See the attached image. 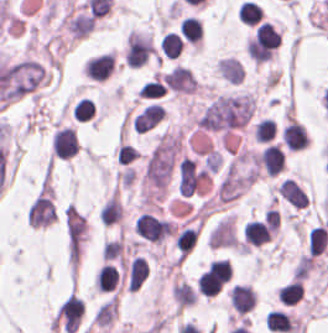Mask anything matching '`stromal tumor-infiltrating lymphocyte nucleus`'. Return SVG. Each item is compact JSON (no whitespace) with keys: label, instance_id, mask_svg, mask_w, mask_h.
<instances>
[{"label":"stromal tumor-infiltrating lymphocyte nucleus","instance_id":"bc302bb0","mask_svg":"<svg viewBox=\"0 0 328 333\" xmlns=\"http://www.w3.org/2000/svg\"><path fill=\"white\" fill-rule=\"evenodd\" d=\"M51 149L54 157L70 159L79 150L75 132L72 128L61 127L55 131L51 138Z\"/></svg>","mask_w":328,"mask_h":333},{"label":"stromal tumor-infiltrating lymphocyte nucleus","instance_id":"52c7bb5b","mask_svg":"<svg viewBox=\"0 0 328 333\" xmlns=\"http://www.w3.org/2000/svg\"><path fill=\"white\" fill-rule=\"evenodd\" d=\"M286 154L281 146L268 143L256 157V163L267 175H276L284 169Z\"/></svg>","mask_w":328,"mask_h":333},{"label":"stromal tumor-infiltrating lymphocyte nucleus","instance_id":"3290ff9b","mask_svg":"<svg viewBox=\"0 0 328 333\" xmlns=\"http://www.w3.org/2000/svg\"><path fill=\"white\" fill-rule=\"evenodd\" d=\"M281 139L286 148L299 150L305 148L309 142L306 128L294 118H287L282 130Z\"/></svg>","mask_w":328,"mask_h":333},{"label":"stromal tumor-infiltrating lymphocyte nucleus","instance_id":"abfb95fc","mask_svg":"<svg viewBox=\"0 0 328 333\" xmlns=\"http://www.w3.org/2000/svg\"><path fill=\"white\" fill-rule=\"evenodd\" d=\"M114 58L112 53L92 56L85 65V76L94 81H103L113 72Z\"/></svg>","mask_w":328,"mask_h":333},{"label":"stromal tumor-infiltrating lymphocyte nucleus","instance_id":"9ea309e8","mask_svg":"<svg viewBox=\"0 0 328 333\" xmlns=\"http://www.w3.org/2000/svg\"><path fill=\"white\" fill-rule=\"evenodd\" d=\"M229 300L237 313H246L251 310L257 301L256 292L247 285H234L230 288Z\"/></svg>","mask_w":328,"mask_h":333},{"label":"stromal tumor-infiltrating lymphocyte nucleus","instance_id":"f3e2335f","mask_svg":"<svg viewBox=\"0 0 328 333\" xmlns=\"http://www.w3.org/2000/svg\"><path fill=\"white\" fill-rule=\"evenodd\" d=\"M276 190L281 198L292 203L293 205L301 209L308 206V196L296 180L288 178L282 180L276 187Z\"/></svg>","mask_w":328,"mask_h":333},{"label":"stromal tumor-infiltrating lymphocyte nucleus","instance_id":"4f13568d","mask_svg":"<svg viewBox=\"0 0 328 333\" xmlns=\"http://www.w3.org/2000/svg\"><path fill=\"white\" fill-rule=\"evenodd\" d=\"M244 242L252 246H261L271 236V230L266 223L250 220L242 229Z\"/></svg>","mask_w":328,"mask_h":333},{"label":"stromal tumor-infiltrating lymphocyte nucleus","instance_id":"2a367800","mask_svg":"<svg viewBox=\"0 0 328 333\" xmlns=\"http://www.w3.org/2000/svg\"><path fill=\"white\" fill-rule=\"evenodd\" d=\"M265 320L271 331L287 333L297 332V319L289 313L278 309H271Z\"/></svg>","mask_w":328,"mask_h":333},{"label":"stromal tumor-infiltrating lymphocyte nucleus","instance_id":"4803ca6d","mask_svg":"<svg viewBox=\"0 0 328 333\" xmlns=\"http://www.w3.org/2000/svg\"><path fill=\"white\" fill-rule=\"evenodd\" d=\"M119 272L110 263H102L95 278V288L102 292H110L117 284Z\"/></svg>","mask_w":328,"mask_h":333},{"label":"stromal tumor-infiltrating lymphocyte nucleus","instance_id":"4245b91a","mask_svg":"<svg viewBox=\"0 0 328 333\" xmlns=\"http://www.w3.org/2000/svg\"><path fill=\"white\" fill-rule=\"evenodd\" d=\"M158 45L164 56L176 58L183 50L184 43L178 32L168 30L159 39Z\"/></svg>","mask_w":328,"mask_h":333},{"label":"stromal tumor-infiltrating lymphocyte nucleus","instance_id":"4c9ddf68","mask_svg":"<svg viewBox=\"0 0 328 333\" xmlns=\"http://www.w3.org/2000/svg\"><path fill=\"white\" fill-rule=\"evenodd\" d=\"M277 298L281 303L288 306L296 305L303 298L302 281L296 278L282 286Z\"/></svg>","mask_w":328,"mask_h":333},{"label":"stromal tumor-infiltrating lymphocyte nucleus","instance_id":"2761f720","mask_svg":"<svg viewBox=\"0 0 328 333\" xmlns=\"http://www.w3.org/2000/svg\"><path fill=\"white\" fill-rule=\"evenodd\" d=\"M180 28L182 36L195 44L201 40L204 34L203 23L190 15L180 22Z\"/></svg>","mask_w":328,"mask_h":333},{"label":"stromal tumor-infiltrating lymphocyte nucleus","instance_id":"3c572f05","mask_svg":"<svg viewBox=\"0 0 328 333\" xmlns=\"http://www.w3.org/2000/svg\"><path fill=\"white\" fill-rule=\"evenodd\" d=\"M197 237L198 229L185 226L181 229L175 239L179 256L185 257L190 252Z\"/></svg>","mask_w":328,"mask_h":333},{"label":"stromal tumor-infiltrating lymphocyte nucleus","instance_id":"42bb06b2","mask_svg":"<svg viewBox=\"0 0 328 333\" xmlns=\"http://www.w3.org/2000/svg\"><path fill=\"white\" fill-rule=\"evenodd\" d=\"M237 18L247 24H255L262 20L263 11L255 2L242 1L238 10Z\"/></svg>","mask_w":328,"mask_h":333},{"label":"stromal tumor-infiltrating lymphocyte nucleus","instance_id":"9e4306bb","mask_svg":"<svg viewBox=\"0 0 328 333\" xmlns=\"http://www.w3.org/2000/svg\"><path fill=\"white\" fill-rule=\"evenodd\" d=\"M166 88V85L154 74L143 82L138 97L158 98L165 92Z\"/></svg>","mask_w":328,"mask_h":333},{"label":"stromal tumor-infiltrating lymphocyte nucleus","instance_id":"04cf8593","mask_svg":"<svg viewBox=\"0 0 328 333\" xmlns=\"http://www.w3.org/2000/svg\"><path fill=\"white\" fill-rule=\"evenodd\" d=\"M276 133L274 121L263 118L252 127V135L255 142H268Z\"/></svg>","mask_w":328,"mask_h":333},{"label":"stromal tumor-infiltrating lymphocyte nucleus","instance_id":"e9af9c67","mask_svg":"<svg viewBox=\"0 0 328 333\" xmlns=\"http://www.w3.org/2000/svg\"><path fill=\"white\" fill-rule=\"evenodd\" d=\"M95 104L87 97H80L71 108L76 121H86L93 116Z\"/></svg>","mask_w":328,"mask_h":333}]
</instances>
